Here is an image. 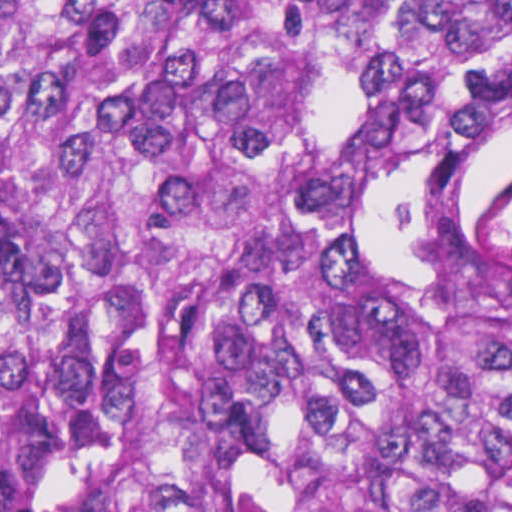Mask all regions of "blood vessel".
<instances>
[{
    "mask_svg": "<svg viewBox=\"0 0 512 512\" xmlns=\"http://www.w3.org/2000/svg\"><path fill=\"white\" fill-rule=\"evenodd\" d=\"M471 254L512 272V164L488 185L475 207Z\"/></svg>",
    "mask_w": 512,
    "mask_h": 512,
    "instance_id": "obj_1",
    "label": "blood vessel"
}]
</instances>
